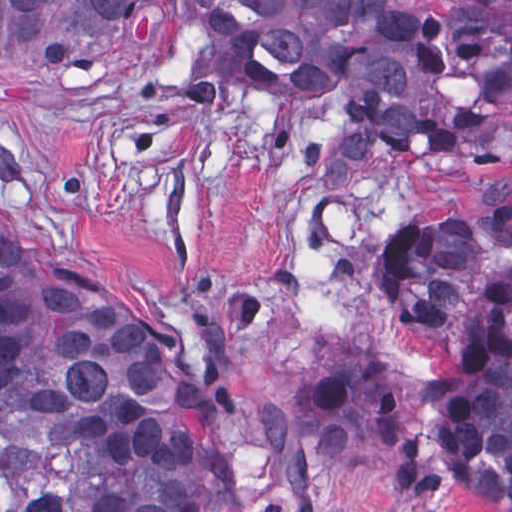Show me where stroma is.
<instances>
[{
    "label": "stroma",
    "instance_id": "35a3bbf8",
    "mask_svg": "<svg viewBox=\"0 0 512 512\" xmlns=\"http://www.w3.org/2000/svg\"><path fill=\"white\" fill-rule=\"evenodd\" d=\"M422 1L512 14V0ZM331 103L238 83L184 18L84 78L0 82V210L65 220L83 281L127 292L140 335L213 404L230 484L210 476V512H405L328 461L299 395L352 359L435 372L433 341L380 304L374 246L512 185V149L492 138L315 180ZM408 512L501 511L448 488Z\"/></svg>",
    "mask_w": 512,
    "mask_h": 512
}]
</instances>
